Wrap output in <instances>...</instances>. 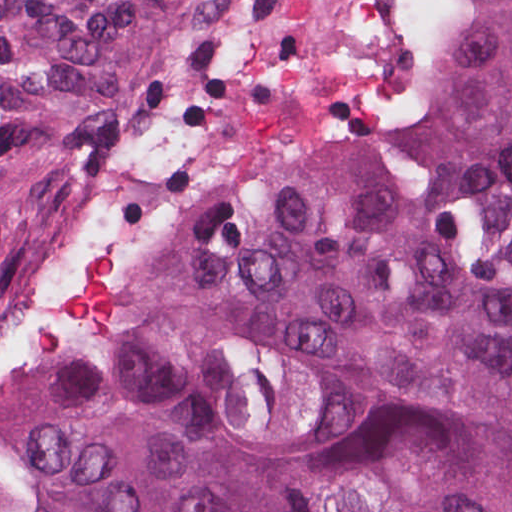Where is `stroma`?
I'll return each instance as SVG.
<instances>
[{
    "label": "stroma",
    "mask_w": 512,
    "mask_h": 512,
    "mask_svg": "<svg viewBox=\"0 0 512 512\" xmlns=\"http://www.w3.org/2000/svg\"><path fill=\"white\" fill-rule=\"evenodd\" d=\"M443 31L444 0H210L173 77L209 123V175L180 243L282 164L409 120Z\"/></svg>",
    "instance_id": "stroma-1"
}]
</instances>
